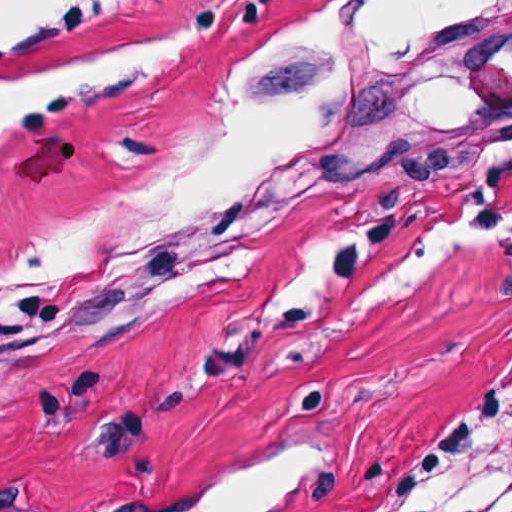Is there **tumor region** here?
Returning a JSON list of instances; mask_svg holds the SVG:
<instances>
[{
	"instance_id": "1",
	"label": "tumor region",
	"mask_w": 512,
	"mask_h": 512,
	"mask_svg": "<svg viewBox=\"0 0 512 512\" xmlns=\"http://www.w3.org/2000/svg\"><path fill=\"white\" fill-rule=\"evenodd\" d=\"M122 359L76 381L107 375ZM512 492V427L485 436L438 488L404 512H478Z\"/></svg>"
}]
</instances>
